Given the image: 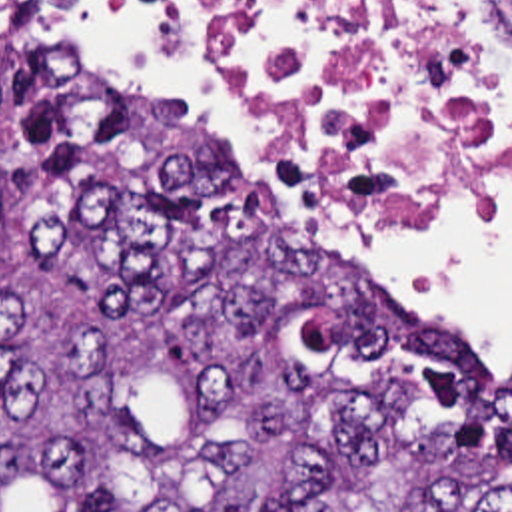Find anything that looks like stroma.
<instances>
[{"label": "stroma", "mask_w": 512, "mask_h": 512, "mask_svg": "<svg viewBox=\"0 0 512 512\" xmlns=\"http://www.w3.org/2000/svg\"><path fill=\"white\" fill-rule=\"evenodd\" d=\"M57 21H59V29H61V37H63V39H65V41H71V43H77V45H81V47H83V51H85V53H87V57H89V61H91V63H95V65H97V67H99V69H103V71H107V69H105V67H103V65H99V63H97V61H95V59H93V57H91V53H89V51H87V49H85V45H83V43H81V41H79V37H77V35H75V33H73V29H71V25H69V21H67V19H65V17H63V13H61V15H59V17H57ZM107 73H109V71H107ZM151 95H153V93H151ZM498 107H500V113H502V119H504V107H502V89H500V99H498ZM246 159H248V157H246ZM248 161H250V163H252V167H256V165H254V161H252V159H248ZM288 203H290V201H288ZM382 203H416V201H382ZM290 209H292V217H294V221H296V223H302V225H308V227H312V229H316V231H318V233H322V235H324V237H328V239H330V241H334V239H332V237H330V235H328V233H324V231H322V229H320V227H318V225H316V223H314V221H312V219H308V217H306V215H304V213H300V211H296V209H294V207H292V205H290ZM334 243H336V241H334ZM416 305H418V307H420V309H422V311H426V309H424V307H422V305H420V303H416ZM426 313H428V315H430V317L440 318V317H436V315H432V313H430V311H426ZM440 320H442V318H440Z\"/></svg>", "instance_id": "1"}]
</instances>
